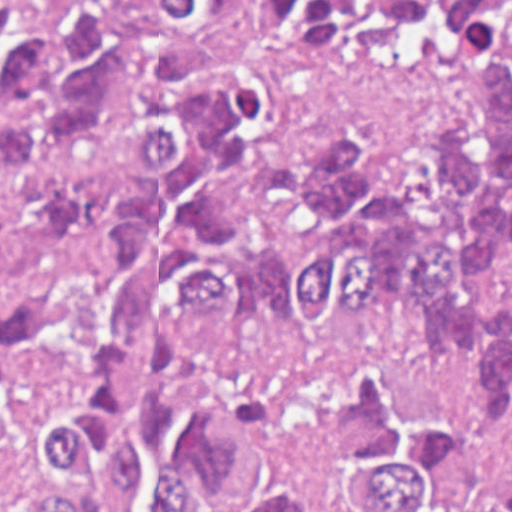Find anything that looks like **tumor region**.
I'll return each instance as SVG.
<instances>
[{
	"instance_id": "tumor-region-1",
	"label": "tumor region",
	"mask_w": 512,
	"mask_h": 512,
	"mask_svg": "<svg viewBox=\"0 0 512 512\" xmlns=\"http://www.w3.org/2000/svg\"><path fill=\"white\" fill-rule=\"evenodd\" d=\"M0 0V443L37 512H512V0H252L299 57L461 44L412 159L265 142L233 0Z\"/></svg>"
}]
</instances>
